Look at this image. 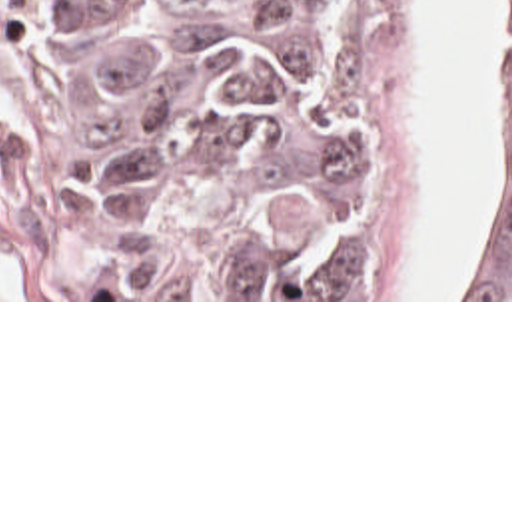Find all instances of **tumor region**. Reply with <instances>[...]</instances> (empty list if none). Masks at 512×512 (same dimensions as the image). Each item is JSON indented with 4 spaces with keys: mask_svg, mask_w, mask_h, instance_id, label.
Listing matches in <instances>:
<instances>
[{
    "mask_svg": "<svg viewBox=\"0 0 512 512\" xmlns=\"http://www.w3.org/2000/svg\"><path fill=\"white\" fill-rule=\"evenodd\" d=\"M75 210L107 298L367 290L345 86L237 0H75ZM450 298H512V0H494L486 242Z\"/></svg>",
    "mask_w": 512,
    "mask_h": 512,
    "instance_id": "1",
    "label": "tumor region"
}]
</instances>
